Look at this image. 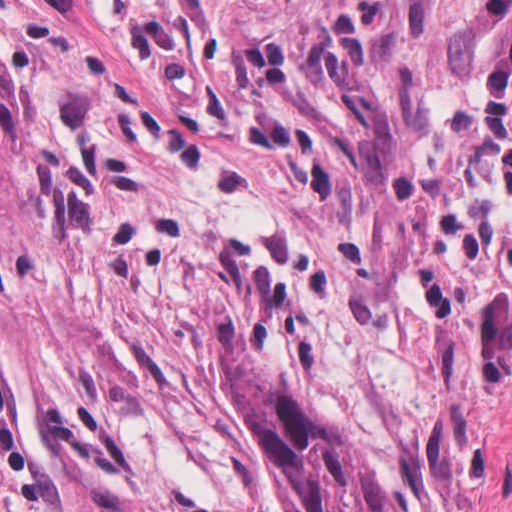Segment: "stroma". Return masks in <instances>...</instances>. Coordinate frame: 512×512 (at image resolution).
<instances>
[{"label":"stroma","mask_w":512,"mask_h":512,"mask_svg":"<svg viewBox=\"0 0 512 512\" xmlns=\"http://www.w3.org/2000/svg\"><path fill=\"white\" fill-rule=\"evenodd\" d=\"M340 36L401 117L370 191L244 56ZM22 218L11 390L57 512H300L223 339L335 422L392 512H512V262L361 0H0Z\"/></svg>","instance_id":"35a3bbf8"}]
</instances>
